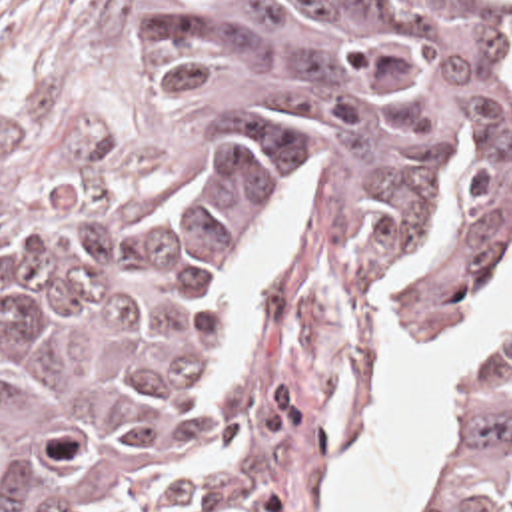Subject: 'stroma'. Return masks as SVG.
<instances>
[{"label":"stroma","mask_w":512,"mask_h":512,"mask_svg":"<svg viewBox=\"0 0 512 512\" xmlns=\"http://www.w3.org/2000/svg\"><path fill=\"white\" fill-rule=\"evenodd\" d=\"M170 162L168 138L142 90V0H0V188H144L160 184ZM511 284L512 260L445 320L395 342L323 512L377 433L405 364L475 324ZM481 372L471 376L415 512L433 511L443 491Z\"/></svg>","instance_id":"1"}]
</instances>
